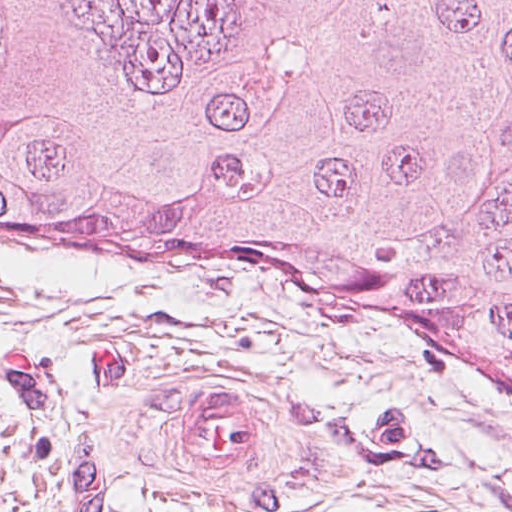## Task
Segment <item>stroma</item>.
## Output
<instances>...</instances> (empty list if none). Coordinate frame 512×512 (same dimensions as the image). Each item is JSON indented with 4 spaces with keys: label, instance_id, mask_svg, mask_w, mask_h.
Instances as JSON below:
<instances>
[{
    "label": "stroma",
    "instance_id": "obj_1",
    "mask_svg": "<svg viewBox=\"0 0 512 512\" xmlns=\"http://www.w3.org/2000/svg\"><path fill=\"white\" fill-rule=\"evenodd\" d=\"M0 512H512V389L345 282L0 249Z\"/></svg>",
    "mask_w": 512,
    "mask_h": 512
}]
</instances>
